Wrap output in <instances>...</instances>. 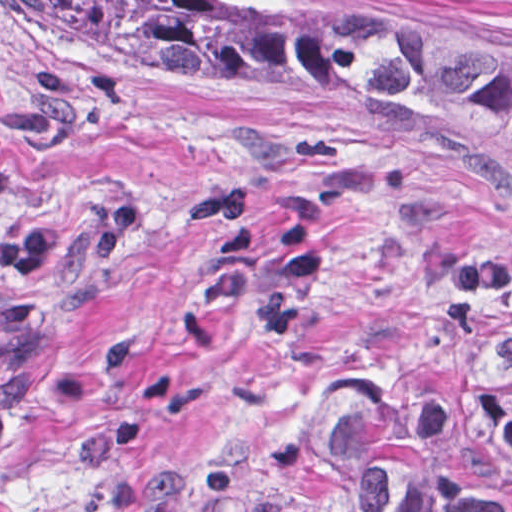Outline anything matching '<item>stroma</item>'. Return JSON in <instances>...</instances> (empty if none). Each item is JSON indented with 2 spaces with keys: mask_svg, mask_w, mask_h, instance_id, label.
Here are the masks:
<instances>
[{
  "mask_svg": "<svg viewBox=\"0 0 512 512\" xmlns=\"http://www.w3.org/2000/svg\"><path fill=\"white\" fill-rule=\"evenodd\" d=\"M512 52V0H217ZM0 179L121 219L15 294L40 336L0 512H233L286 411L419 420L512 329V192L349 104L128 62L0 0Z\"/></svg>",
  "mask_w": 512,
  "mask_h": 512,
  "instance_id": "1",
  "label": "stroma"
}]
</instances>
